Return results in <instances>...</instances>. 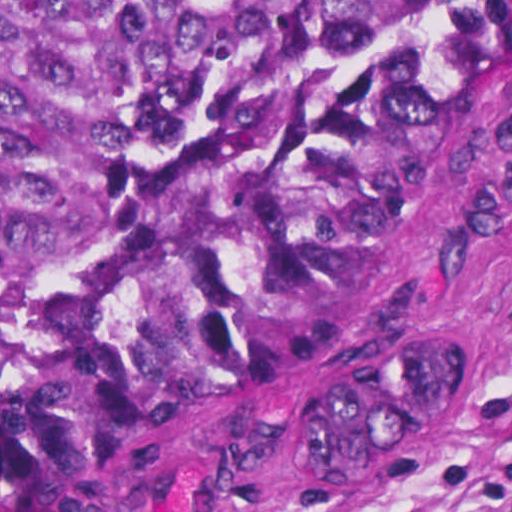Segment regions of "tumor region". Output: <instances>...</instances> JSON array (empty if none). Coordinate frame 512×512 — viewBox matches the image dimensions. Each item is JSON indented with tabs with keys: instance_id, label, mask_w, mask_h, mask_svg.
<instances>
[{
	"instance_id": "e687c5a6",
	"label": "tumor region",
	"mask_w": 512,
	"mask_h": 512,
	"mask_svg": "<svg viewBox=\"0 0 512 512\" xmlns=\"http://www.w3.org/2000/svg\"><path fill=\"white\" fill-rule=\"evenodd\" d=\"M511 57L512 0H0V494L65 493L312 350ZM466 367L432 322L313 376L302 468L385 478Z\"/></svg>"
}]
</instances>
